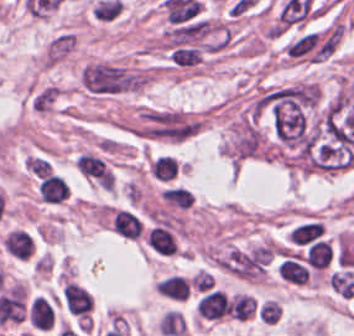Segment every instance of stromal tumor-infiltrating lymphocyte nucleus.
Listing matches in <instances>:
<instances>
[{"label": "stromal tumor-infiltrating lymphocyte nucleus", "mask_w": 354, "mask_h": 336, "mask_svg": "<svg viewBox=\"0 0 354 336\" xmlns=\"http://www.w3.org/2000/svg\"><path fill=\"white\" fill-rule=\"evenodd\" d=\"M26 318L31 327L49 329L55 321L54 302L46 296H33L28 301Z\"/></svg>", "instance_id": "1"}, {"label": "stromal tumor-infiltrating lymphocyte nucleus", "mask_w": 354, "mask_h": 336, "mask_svg": "<svg viewBox=\"0 0 354 336\" xmlns=\"http://www.w3.org/2000/svg\"><path fill=\"white\" fill-rule=\"evenodd\" d=\"M146 241L158 253L173 254L178 244L168 229L154 226L148 229Z\"/></svg>", "instance_id": "2"}, {"label": "stromal tumor-infiltrating lymphocyte nucleus", "mask_w": 354, "mask_h": 336, "mask_svg": "<svg viewBox=\"0 0 354 336\" xmlns=\"http://www.w3.org/2000/svg\"><path fill=\"white\" fill-rule=\"evenodd\" d=\"M140 222L131 212L116 209L112 216V229L123 236H137L139 234Z\"/></svg>", "instance_id": "3"}, {"label": "stromal tumor-infiltrating lymphocyte nucleus", "mask_w": 354, "mask_h": 336, "mask_svg": "<svg viewBox=\"0 0 354 336\" xmlns=\"http://www.w3.org/2000/svg\"><path fill=\"white\" fill-rule=\"evenodd\" d=\"M176 160L174 156L165 154L155 155L149 164V172L158 181H170L174 178Z\"/></svg>", "instance_id": "4"}, {"label": "stromal tumor-infiltrating lymphocyte nucleus", "mask_w": 354, "mask_h": 336, "mask_svg": "<svg viewBox=\"0 0 354 336\" xmlns=\"http://www.w3.org/2000/svg\"><path fill=\"white\" fill-rule=\"evenodd\" d=\"M157 287L164 295L182 300L187 294L189 284L181 275L174 273L160 279Z\"/></svg>", "instance_id": "5"}, {"label": "stromal tumor-infiltrating lymphocyte nucleus", "mask_w": 354, "mask_h": 336, "mask_svg": "<svg viewBox=\"0 0 354 336\" xmlns=\"http://www.w3.org/2000/svg\"><path fill=\"white\" fill-rule=\"evenodd\" d=\"M159 326L164 334H179L185 326L184 318L180 311L168 309Z\"/></svg>", "instance_id": "6"}, {"label": "stromal tumor-infiltrating lymphocyte nucleus", "mask_w": 354, "mask_h": 336, "mask_svg": "<svg viewBox=\"0 0 354 336\" xmlns=\"http://www.w3.org/2000/svg\"><path fill=\"white\" fill-rule=\"evenodd\" d=\"M235 303L240 320H247L254 311V296L240 293L235 296Z\"/></svg>", "instance_id": "7"}, {"label": "stromal tumor-infiltrating lymphocyte nucleus", "mask_w": 354, "mask_h": 336, "mask_svg": "<svg viewBox=\"0 0 354 336\" xmlns=\"http://www.w3.org/2000/svg\"><path fill=\"white\" fill-rule=\"evenodd\" d=\"M178 172H179V163H178V159H177L167 182L170 181L171 179H173L174 177H176Z\"/></svg>", "instance_id": "8"}, {"label": "stromal tumor-infiltrating lymphocyte nucleus", "mask_w": 354, "mask_h": 336, "mask_svg": "<svg viewBox=\"0 0 354 336\" xmlns=\"http://www.w3.org/2000/svg\"><path fill=\"white\" fill-rule=\"evenodd\" d=\"M90 306H91V310H92V307H93V297L91 295V299H90Z\"/></svg>", "instance_id": "9"}]
</instances>
